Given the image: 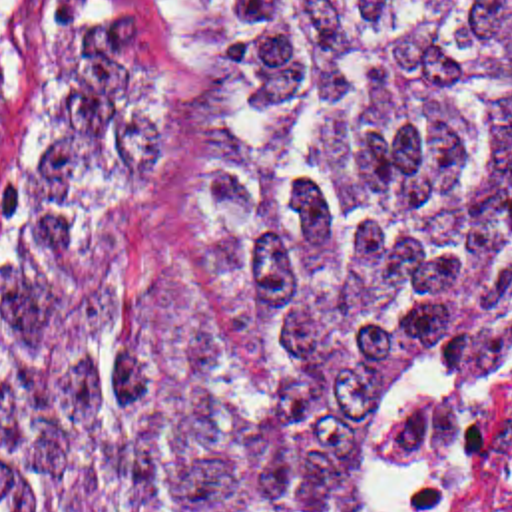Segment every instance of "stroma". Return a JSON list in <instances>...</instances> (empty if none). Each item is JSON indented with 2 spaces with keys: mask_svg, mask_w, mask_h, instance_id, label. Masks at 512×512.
I'll return each mask as SVG.
<instances>
[{
  "mask_svg": "<svg viewBox=\"0 0 512 512\" xmlns=\"http://www.w3.org/2000/svg\"><path fill=\"white\" fill-rule=\"evenodd\" d=\"M106 0H0V326L28 193L68 97L90 16Z\"/></svg>",
  "mask_w": 512,
  "mask_h": 512,
  "instance_id": "stroma-1",
  "label": "stroma"
}]
</instances>
